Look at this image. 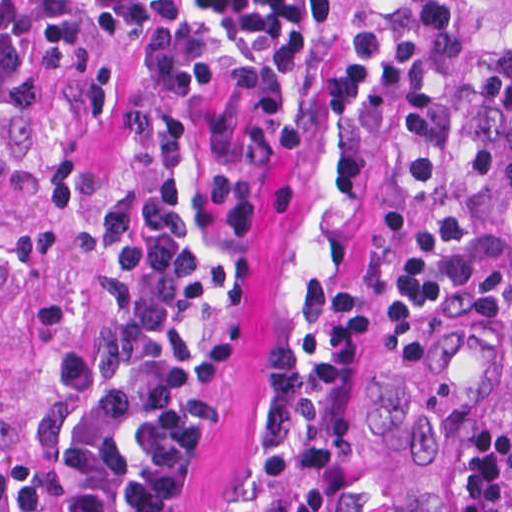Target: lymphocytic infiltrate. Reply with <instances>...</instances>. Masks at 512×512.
Returning <instances> with one entry per match:
<instances>
[{"label":"lymphocytic infiltrate","mask_w":512,"mask_h":512,"mask_svg":"<svg viewBox=\"0 0 512 512\" xmlns=\"http://www.w3.org/2000/svg\"><path fill=\"white\" fill-rule=\"evenodd\" d=\"M86 29L110 51L145 56L151 85L163 93L212 82L204 30L241 48L263 78L259 143L271 162H295L310 143L297 82L315 51L330 47L321 106L336 119L366 108L393 79L396 61V41L382 30L352 42L347 0H0V80L28 88L78 63ZM118 253L124 273H103L101 282L112 333L63 362L34 457L9 473L19 512H110L121 434L141 410L158 421L137 441L143 456L124 497L128 512H194L196 475L227 403L235 332L196 338L208 292L173 179L160 175L145 194L137 234ZM328 322L319 364L304 366L283 346L270 357L265 415L281 439L261 474L291 494L288 512H330L348 472L370 298L358 290L338 297Z\"/></svg>","instance_id":"obj_1"}]
</instances>
